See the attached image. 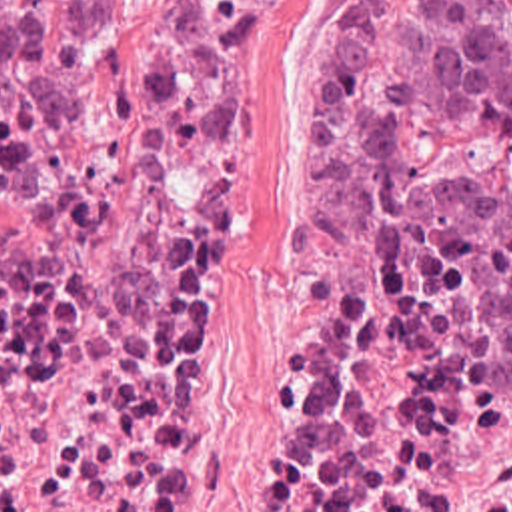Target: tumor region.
<instances>
[{"mask_svg":"<svg viewBox=\"0 0 512 512\" xmlns=\"http://www.w3.org/2000/svg\"><path fill=\"white\" fill-rule=\"evenodd\" d=\"M129 0H0V99L87 79L95 25ZM439 129L512 135V0H343L327 25L309 137V213L391 229L431 319L512 347V193L445 203L389 183Z\"/></svg>","mask_w":512,"mask_h":512,"instance_id":"obj_1","label":"tumor region"}]
</instances>
